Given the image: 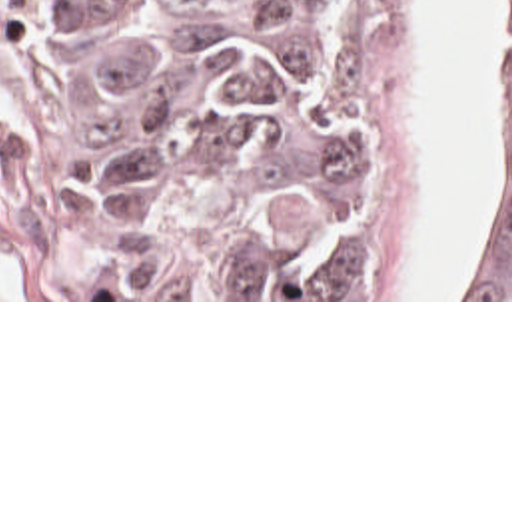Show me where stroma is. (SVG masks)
Wrapping results in <instances>:
<instances>
[{"mask_svg":"<svg viewBox=\"0 0 512 512\" xmlns=\"http://www.w3.org/2000/svg\"><path fill=\"white\" fill-rule=\"evenodd\" d=\"M323 56L353 108L365 170L363 298H107L75 210V0H0V302H512L395 298L409 232L420 128L409 0H237ZM492 108L484 146L482 238L494 168V0H484Z\"/></svg>","mask_w":512,"mask_h":512,"instance_id":"1","label":"stroma"}]
</instances>
